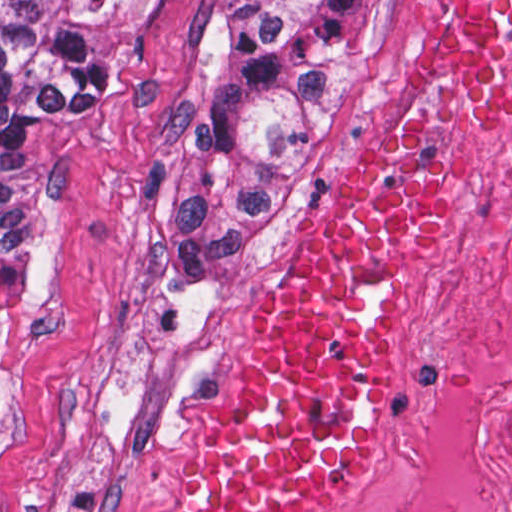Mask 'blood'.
Instances as JSON below:
<instances>
[{
  "mask_svg": "<svg viewBox=\"0 0 512 512\" xmlns=\"http://www.w3.org/2000/svg\"><path fill=\"white\" fill-rule=\"evenodd\" d=\"M423 108L512 121V0H435L407 93L264 322L246 398L208 443L179 512H309L344 487L372 435L384 304L441 213Z\"/></svg>",
  "mask_w": 512,
  "mask_h": 512,
  "instance_id": "obj_1",
  "label": "blood"
}]
</instances>
